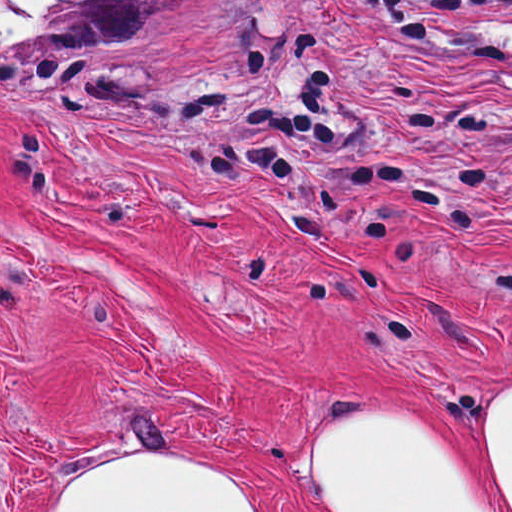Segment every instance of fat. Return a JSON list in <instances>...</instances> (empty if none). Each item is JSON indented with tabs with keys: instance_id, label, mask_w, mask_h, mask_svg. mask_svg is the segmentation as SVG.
<instances>
[{
	"instance_id": "fat-1",
	"label": "fat",
	"mask_w": 512,
	"mask_h": 512,
	"mask_svg": "<svg viewBox=\"0 0 512 512\" xmlns=\"http://www.w3.org/2000/svg\"><path fill=\"white\" fill-rule=\"evenodd\" d=\"M305 452L348 512H512V386L491 433L504 492L452 440L354 408L309 420ZM43 512H252L239 486L187 457L115 452L83 461Z\"/></svg>"
}]
</instances>
